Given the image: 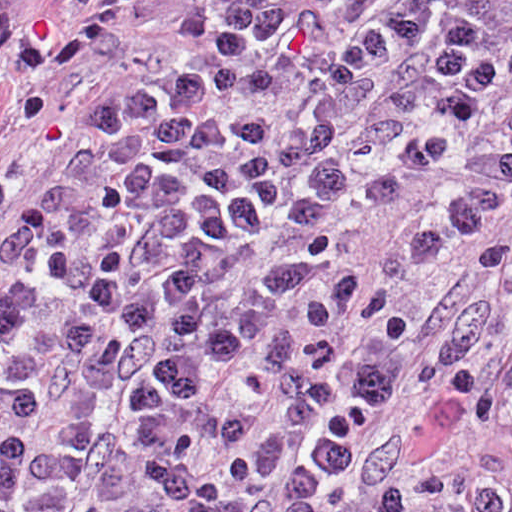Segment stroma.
<instances>
[{"instance_id": "stroma-1", "label": "stroma", "mask_w": 512, "mask_h": 512, "mask_svg": "<svg viewBox=\"0 0 512 512\" xmlns=\"http://www.w3.org/2000/svg\"><path fill=\"white\" fill-rule=\"evenodd\" d=\"M206 0H156L139 5L121 24L117 61L68 73L48 71L61 43V0H8L24 40L34 45L38 84L53 110V124L21 179L1 205V0H0V512H1V229L25 218L37 203L61 156L93 118L99 88L157 65L187 36ZM442 178L413 176L398 182L378 213L351 243V255L411 318L413 342L401 379L369 434H393L391 459L377 464L355 490L346 512H371L373 498L408 476H465L512 495V439L487 432L466 414L452 428L433 422L420 382L432 337L442 334L474 302L481 281L475 261L483 246L479 227L438 240L426 257L409 256V231ZM282 477L256 484L251 512H280ZM512 512V499L499 511Z\"/></svg>"}]
</instances>
